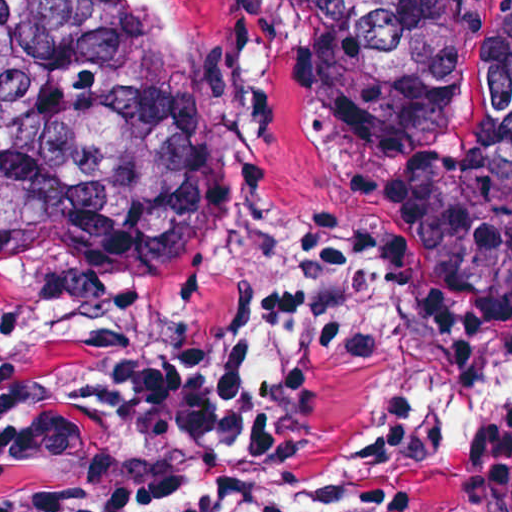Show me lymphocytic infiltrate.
I'll return each mask as SVG.
<instances>
[{"label":"lymphocytic infiltrate","instance_id":"1","mask_svg":"<svg viewBox=\"0 0 512 512\" xmlns=\"http://www.w3.org/2000/svg\"><path fill=\"white\" fill-rule=\"evenodd\" d=\"M390 332L388 221L333 211L314 264L257 310L243 379L139 348L0 382V512H357L356 472L304 431L298 392Z\"/></svg>","mask_w":512,"mask_h":512}]
</instances>
